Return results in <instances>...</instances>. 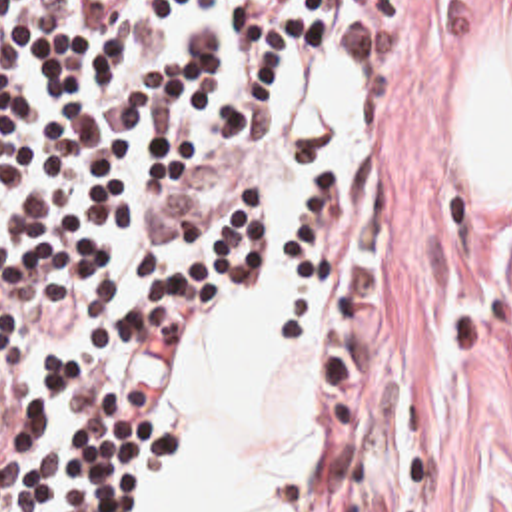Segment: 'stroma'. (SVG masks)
Returning <instances> with one entry per match:
<instances>
[{
	"instance_id": "1",
	"label": "stroma",
	"mask_w": 512,
	"mask_h": 512,
	"mask_svg": "<svg viewBox=\"0 0 512 512\" xmlns=\"http://www.w3.org/2000/svg\"><path fill=\"white\" fill-rule=\"evenodd\" d=\"M512 0H366L338 81V179L360 243L326 271L216 297L162 391L170 508L180 377L228 305L328 285L304 512H512V209L477 193L465 105Z\"/></svg>"
}]
</instances>
